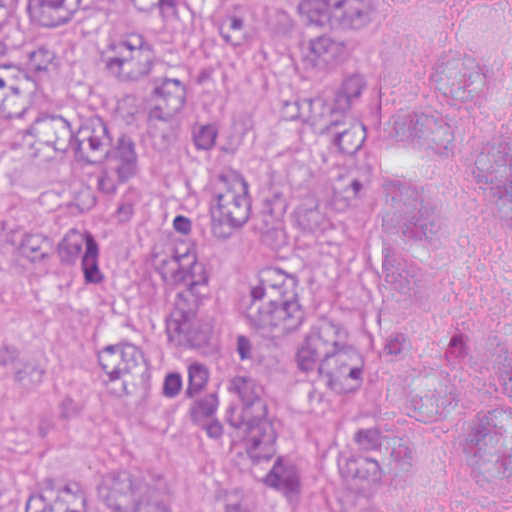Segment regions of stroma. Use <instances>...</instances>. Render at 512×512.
Listing matches in <instances>:
<instances>
[{"label": "stroma", "mask_w": 512, "mask_h": 512, "mask_svg": "<svg viewBox=\"0 0 512 512\" xmlns=\"http://www.w3.org/2000/svg\"><path fill=\"white\" fill-rule=\"evenodd\" d=\"M130 0H95L94 21ZM367 35H343L333 69H383L409 59L406 0H366ZM212 0H186L181 14L145 37L164 47L222 98L231 118L208 152L168 148L142 122L122 81L90 45L69 37L59 52L66 95L141 143L120 196L102 210H76L39 190L0 180V207L113 253L86 284H22L0 268V451L80 445L114 455L156 479L175 512H213L190 484L199 456L190 429L166 414L115 405L94 380L89 352L98 326L133 286L120 270L115 233L149 199L199 189V163L219 149L271 168L296 156L304 111L330 74L299 55V11L260 0L249 39H224L208 20ZM475 465V434L449 420L426 439L414 512H443ZM512 512V499L497 504Z\"/></svg>", "instance_id": "1"}]
</instances>
